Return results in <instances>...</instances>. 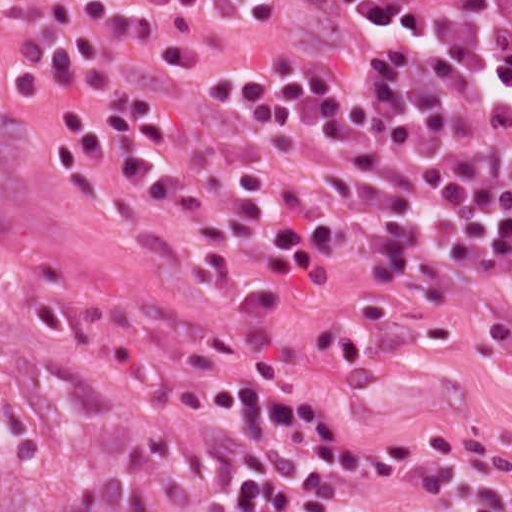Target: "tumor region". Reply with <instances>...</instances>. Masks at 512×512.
I'll return each instance as SVG.
<instances>
[{
    "label": "tumor region",
    "mask_w": 512,
    "mask_h": 512,
    "mask_svg": "<svg viewBox=\"0 0 512 512\" xmlns=\"http://www.w3.org/2000/svg\"><path fill=\"white\" fill-rule=\"evenodd\" d=\"M0 512H177L45 396L0 335Z\"/></svg>",
    "instance_id": "tumor-region-1"
}]
</instances>
